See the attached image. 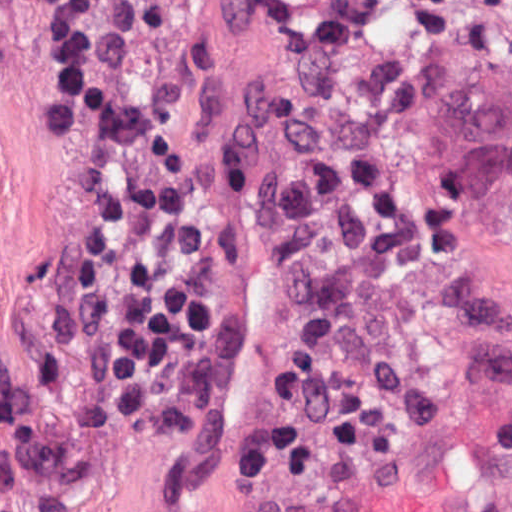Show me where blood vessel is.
I'll list each match as a JSON object with an SVG mask.
<instances>
[{"label":"blood vessel","mask_w":512,"mask_h":512,"mask_svg":"<svg viewBox=\"0 0 512 512\" xmlns=\"http://www.w3.org/2000/svg\"><path fill=\"white\" fill-rule=\"evenodd\" d=\"M251 512H512V420L292 485Z\"/></svg>","instance_id":"blood-vessel-1"}]
</instances>
